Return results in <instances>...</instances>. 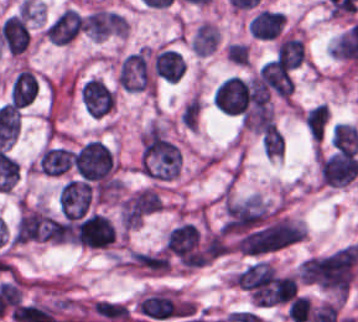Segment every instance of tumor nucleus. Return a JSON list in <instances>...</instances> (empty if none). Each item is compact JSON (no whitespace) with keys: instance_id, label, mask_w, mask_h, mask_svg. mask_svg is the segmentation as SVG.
<instances>
[{"instance_id":"13","label":"tumor nucleus","mask_w":358,"mask_h":322,"mask_svg":"<svg viewBox=\"0 0 358 322\" xmlns=\"http://www.w3.org/2000/svg\"><path fill=\"white\" fill-rule=\"evenodd\" d=\"M156 75L177 81L184 72V61L180 54L168 48H161L154 57Z\"/></svg>"},{"instance_id":"1","label":"tumor nucleus","mask_w":358,"mask_h":322,"mask_svg":"<svg viewBox=\"0 0 358 322\" xmlns=\"http://www.w3.org/2000/svg\"><path fill=\"white\" fill-rule=\"evenodd\" d=\"M116 82L130 92H154L155 79L147 48L141 47L121 60Z\"/></svg>"},{"instance_id":"3","label":"tumor nucleus","mask_w":358,"mask_h":322,"mask_svg":"<svg viewBox=\"0 0 358 322\" xmlns=\"http://www.w3.org/2000/svg\"><path fill=\"white\" fill-rule=\"evenodd\" d=\"M319 173L330 186H343L358 173V158L351 149H340L321 155Z\"/></svg>"},{"instance_id":"9","label":"tumor nucleus","mask_w":358,"mask_h":322,"mask_svg":"<svg viewBox=\"0 0 358 322\" xmlns=\"http://www.w3.org/2000/svg\"><path fill=\"white\" fill-rule=\"evenodd\" d=\"M270 89L289 103L292 86L287 67L276 56L261 67Z\"/></svg>"},{"instance_id":"10","label":"tumor nucleus","mask_w":358,"mask_h":322,"mask_svg":"<svg viewBox=\"0 0 358 322\" xmlns=\"http://www.w3.org/2000/svg\"><path fill=\"white\" fill-rule=\"evenodd\" d=\"M72 153L63 146H43L37 159L40 172L59 175L70 167Z\"/></svg>"},{"instance_id":"17","label":"tumor nucleus","mask_w":358,"mask_h":322,"mask_svg":"<svg viewBox=\"0 0 358 322\" xmlns=\"http://www.w3.org/2000/svg\"><path fill=\"white\" fill-rule=\"evenodd\" d=\"M199 111L200 100L197 95L193 93L181 110L180 119L182 123L185 124L188 128L196 129Z\"/></svg>"},{"instance_id":"15","label":"tumor nucleus","mask_w":358,"mask_h":322,"mask_svg":"<svg viewBox=\"0 0 358 322\" xmlns=\"http://www.w3.org/2000/svg\"><path fill=\"white\" fill-rule=\"evenodd\" d=\"M329 110L326 103H319L304 112L302 118L305 122L308 133L314 139L322 138L327 120Z\"/></svg>"},{"instance_id":"16","label":"tumor nucleus","mask_w":358,"mask_h":322,"mask_svg":"<svg viewBox=\"0 0 358 322\" xmlns=\"http://www.w3.org/2000/svg\"><path fill=\"white\" fill-rule=\"evenodd\" d=\"M261 148L270 157L281 155L284 149V140L275 124L271 123L264 133L261 139Z\"/></svg>"},{"instance_id":"12","label":"tumor nucleus","mask_w":358,"mask_h":322,"mask_svg":"<svg viewBox=\"0 0 358 322\" xmlns=\"http://www.w3.org/2000/svg\"><path fill=\"white\" fill-rule=\"evenodd\" d=\"M284 20L279 11L260 10L248 24L249 33L260 39H271L275 36Z\"/></svg>"},{"instance_id":"7","label":"tumor nucleus","mask_w":358,"mask_h":322,"mask_svg":"<svg viewBox=\"0 0 358 322\" xmlns=\"http://www.w3.org/2000/svg\"><path fill=\"white\" fill-rule=\"evenodd\" d=\"M83 16L73 7H66L47 26L45 35L49 41L67 43L79 31Z\"/></svg>"},{"instance_id":"4","label":"tumor nucleus","mask_w":358,"mask_h":322,"mask_svg":"<svg viewBox=\"0 0 358 322\" xmlns=\"http://www.w3.org/2000/svg\"><path fill=\"white\" fill-rule=\"evenodd\" d=\"M79 100L92 118H104L114 108L115 95L101 78L88 77L79 87Z\"/></svg>"},{"instance_id":"2","label":"tumor nucleus","mask_w":358,"mask_h":322,"mask_svg":"<svg viewBox=\"0 0 358 322\" xmlns=\"http://www.w3.org/2000/svg\"><path fill=\"white\" fill-rule=\"evenodd\" d=\"M71 163L85 181H105L112 169L110 151L98 139H90L79 147L72 154Z\"/></svg>"},{"instance_id":"11","label":"tumor nucleus","mask_w":358,"mask_h":322,"mask_svg":"<svg viewBox=\"0 0 358 322\" xmlns=\"http://www.w3.org/2000/svg\"><path fill=\"white\" fill-rule=\"evenodd\" d=\"M38 81L29 67H22L13 78L10 98L13 105H27L34 99Z\"/></svg>"},{"instance_id":"6","label":"tumor nucleus","mask_w":358,"mask_h":322,"mask_svg":"<svg viewBox=\"0 0 358 322\" xmlns=\"http://www.w3.org/2000/svg\"><path fill=\"white\" fill-rule=\"evenodd\" d=\"M83 30L95 39L125 35V20L117 13L107 10H94L84 17Z\"/></svg>"},{"instance_id":"5","label":"tumor nucleus","mask_w":358,"mask_h":322,"mask_svg":"<svg viewBox=\"0 0 358 322\" xmlns=\"http://www.w3.org/2000/svg\"><path fill=\"white\" fill-rule=\"evenodd\" d=\"M162 209V201L155 190L140 189L123 198L120 204V217L125 221H141Z\"/></svg>"},{"instance_id":"8","label":"tumor nucleus","mask_w":358,"mask_h":322,"mask_svg":"<svg viewBox=\"0 0 358 322\" xmlns=\"http://www.w3.org/2000/svg\"><path fill=\"white\" fill-rule=\"evenodd\" d=\"M0 38L9 53H18L27 46L28 31L21 17L6 16L0 24Z\"/></svg>"},{"instance_id":"14","label":"tumor nucleus","mask_w":358,"mask_h":322,"mask_svg":"<svg viewBox=\"0 0 358 322\" xmlns=\"http://www.w3.org/2000/svg\"><path fill=\"white\" fill-rule=\"evenodd\" d=\"M275 56L289 67H296L305 58L303 38L284 36L281 37L275 48Z\"/></svg>"}]
</instances>
